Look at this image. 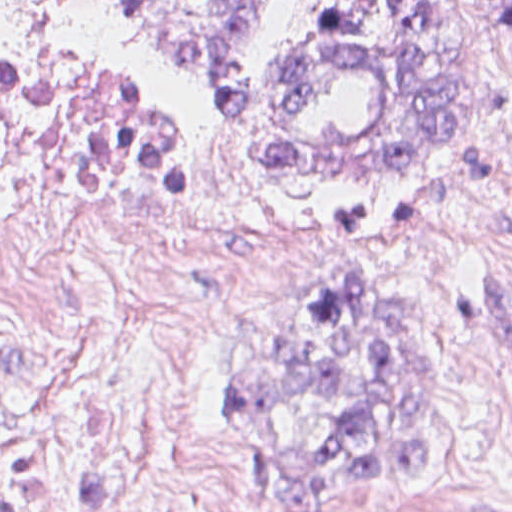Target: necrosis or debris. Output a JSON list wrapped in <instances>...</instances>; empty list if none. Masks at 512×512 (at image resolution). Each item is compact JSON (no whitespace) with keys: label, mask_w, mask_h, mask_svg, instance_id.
<instances>
[{"label":"necrosis or debris","mask_w":512,"mask_h":512,"mask_svg":"<svg viewBox=\"0 0 512 512\" xmlns=\"http://www.w3.org/2000/svg\"><path fill=\"white\" fill-rule=\"evenodd\" d=\"M124 50L0 61V512H238L190 351L281 284Z\"/></svg>","instance_id":"1"}]
</instances>
